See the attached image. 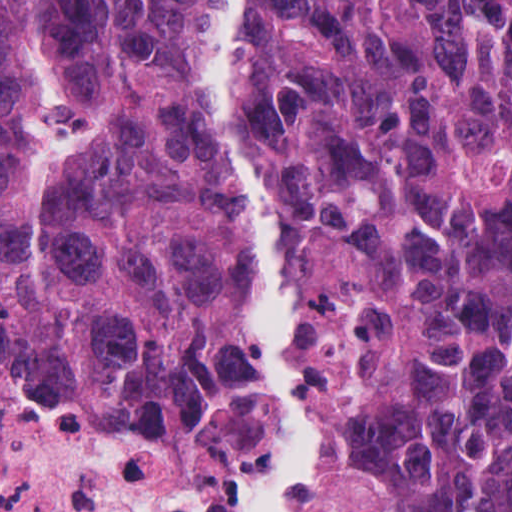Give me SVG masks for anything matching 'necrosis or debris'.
Listing matches in <instances>:
<instances>
[{
  "label": "necrosis or debris",
  "mask_w": 512,
  "mask_h": 512,
  "mask_svg": "<svg viewBox=\"0 0 512 512\" xmlns=\"http://www.w3.org/2000/svg\"><path fill=\"white\" fill-rule=\"evenodd\" d=\"M0 512H237L196 462L98 427L0 374Z\"/></svg>",
  "instance_id": "necrosis-or-debris-1"
}]
</instances>
